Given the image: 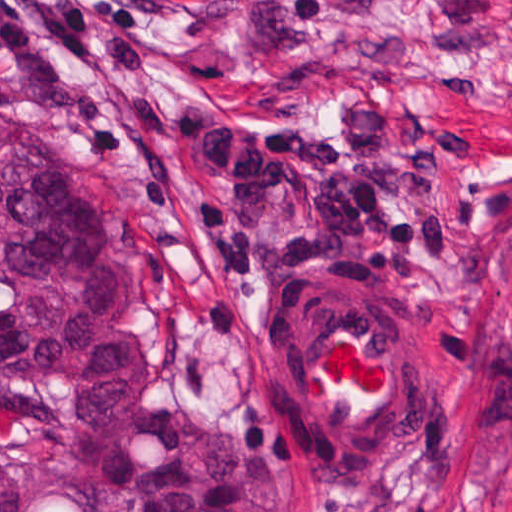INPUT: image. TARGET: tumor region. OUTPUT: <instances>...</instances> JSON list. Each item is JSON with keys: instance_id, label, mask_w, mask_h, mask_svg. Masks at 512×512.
I'll use <instances>...</instances> for the list:
<instances>
[{"instance_id": "tumor-region-1", "label": "tumor region", "mask_w": 512, "mask_h": 512, "mask_svg": "<svg viewBox=\"0 0 512 512\" xmlns=\"http://www.w3.org/2000/svg\"><path fill=\"white\" fill-rule=\"evenodd\" d=\"M253 428L145 393L71 161L0 125V512H303Z\"/></svg>"}]
</instances>
